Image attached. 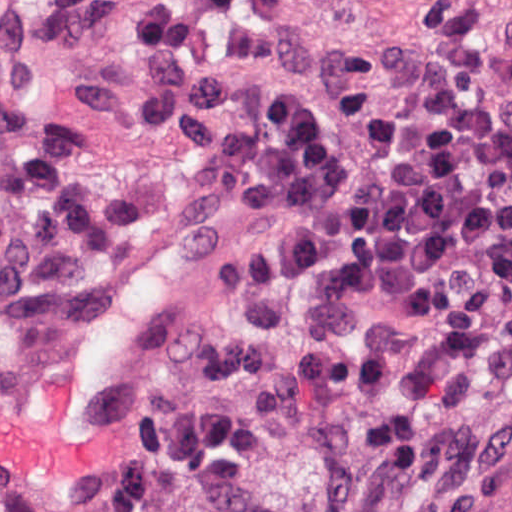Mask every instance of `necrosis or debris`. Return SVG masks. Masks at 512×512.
Segmentation results:
<instances>
[{
    "label": "necrosis or debris",
    "instance_id": "necrosis-or-debris-1",
    "mask_svg": "<svg viewBox=\"0 0 512 512\" xmlns=\"http://www.w3.org/2000/svg\"><path fill=\"white\" fill-rule=\"evenodd\" d=\"M267 64L381 67L417 111L512 117V0H241Z\"/></svg>",
    "mask_w": 512,
    "mask_h": 512
}]
</instances>
